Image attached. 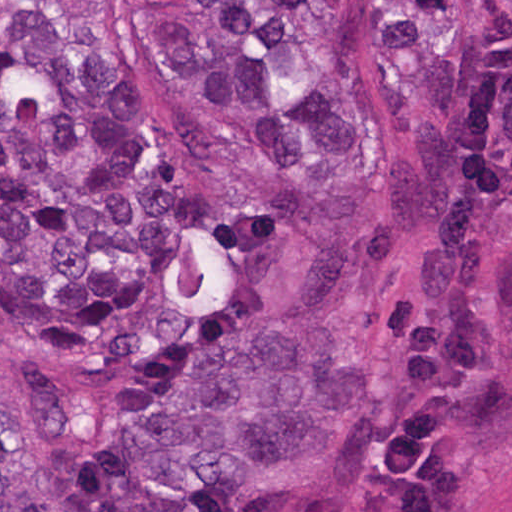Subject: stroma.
Here are the masks:
<instances>
[{
    "label": "stroma",
    "instance_id": "35a3bbf8",
    "mask_svg": "<svg viewBox=\"0 0 512 512\" xmlns=\"http://www.w3.org/2000/svg\"><path fill=\"white\" fill-rule=\"evenodd\" d=\"M0 29L105 64L194 183L247 181L238 122L145 0H0ZM293 512H512V0H478L449 191L371 291L365 393Z\"/></svg>",
    "mask_w": 512,
    "mask_h": 512
}]
</instances>
